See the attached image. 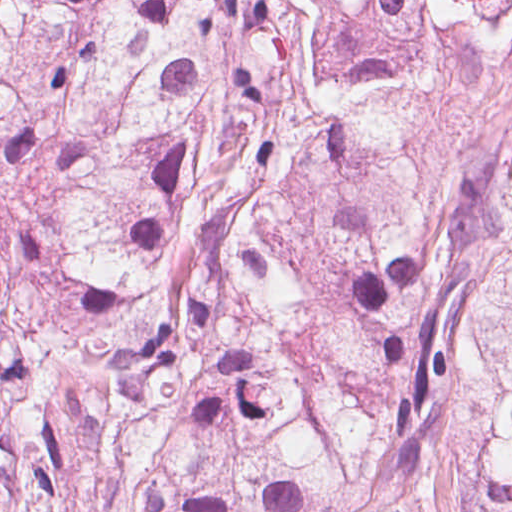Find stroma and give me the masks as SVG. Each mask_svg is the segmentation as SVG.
<instances>
[{"label": "stroma", "instance_id": "35a3bbf8", "mask_svg": "<svg viewBox=\"0 0 512 512\" xmlns=\"http://www.w3.org/2000/svg\"><path fill=\"white\" fill-rule=\"evenodd\" d=\"M432 66L398 115L399 170L416 197L461 182L466 157L512 125V40L484 65L439 31L423 37ZM472 462L459 437L437 434L421 464L408 512H470Z\"/></svg>", "mask_w": 512, "mask_h": 512}]
</instances>
